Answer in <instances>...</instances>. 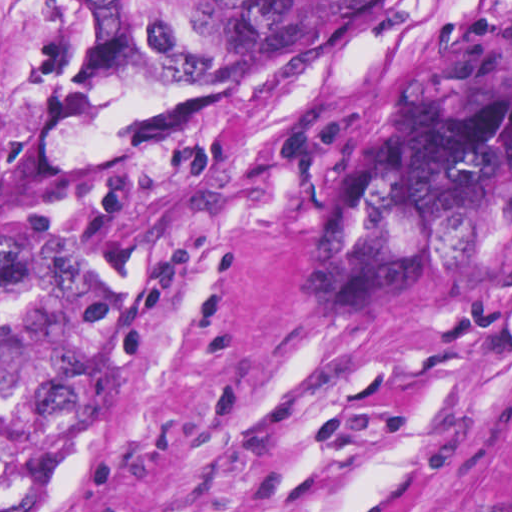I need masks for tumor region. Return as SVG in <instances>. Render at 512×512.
<instances>
[{"mask_svg":"<svg viewBox=\"0 0 512 512\" xmlns=\"http://www.w3.org/2000/svg\"><path fill=\"white\" fill-rule=\"evenodd\" d=\"M93 73L229 92L46 159L0 244V512H100L128 465L153 280L244 158L265 91L350 50L392 0H74Z\"/></svg>","mask_w":512,"mask_h":512,"instance_id":"1","label":"tumor region"}]
</instances>
